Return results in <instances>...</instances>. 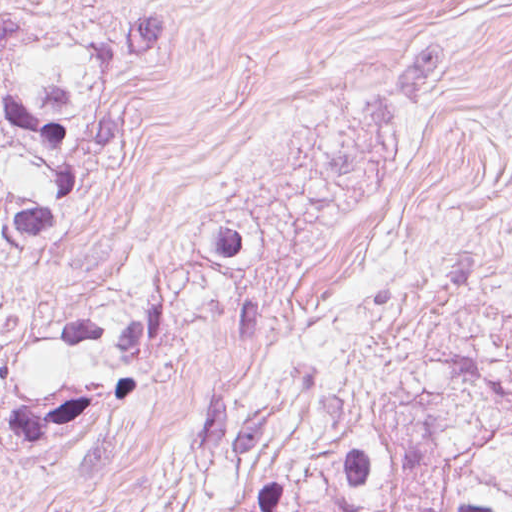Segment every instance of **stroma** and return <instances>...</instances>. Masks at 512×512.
Wrapping results in <instances>:
<instances>
[{"label": "stroma", "instance_id": "35a3bbf8", "mask_svg": "<svg viewBox=\"0 0 512 512\" xmlns=\"http://www.w3.org/2000/svg\"><path fill=\"white\" fill-rule=\"evenodd\" d=\"M464 348L512 386V0H322L192 400Z\"/></svg>", "mask_w": 512, "mask_h": 512}]
</instances>
